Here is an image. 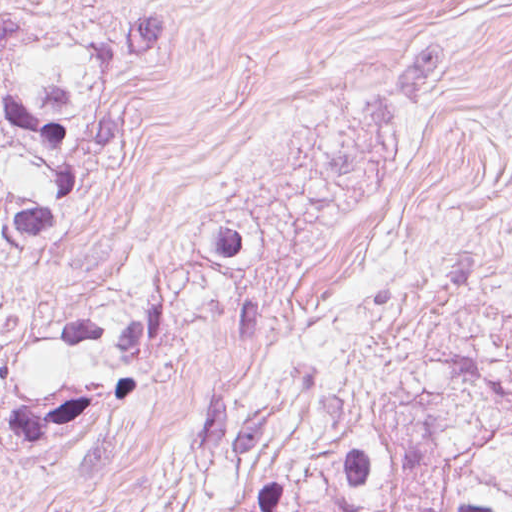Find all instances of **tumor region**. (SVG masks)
<instances>
[{"instance_id": "e687c5a6", "label": "tumor region", "mask_w": 512, "mask_h": 512, "mask_svg": "<svg viewBox=\"0 0 512 512\" xmlns=\"http://www.w3.org/2000/svg\"><path fill=\"white\" fill-rule=\"evenodd\" d=\"M156 512H512V386L468 348L393 389L247 371L191 401Z\"/></svg>"}]
</instances>
